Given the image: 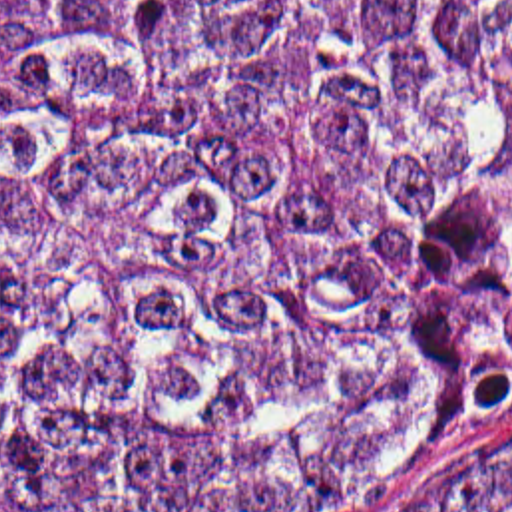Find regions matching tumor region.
<instances>
[{"mask_svg":"<svg viewBox=\"0 0 512 512\" xmlns=\"http://www.w3.org/2000/svg\"><path fill=\"white\" fill-rule=\"evenodd\" d=\"M508 424L512 0H0V509L359 512Z\"/></svg>","mask_w":512,"mask_h":512,"instance_id":"1","label":"tumor region"}]
</instances>
